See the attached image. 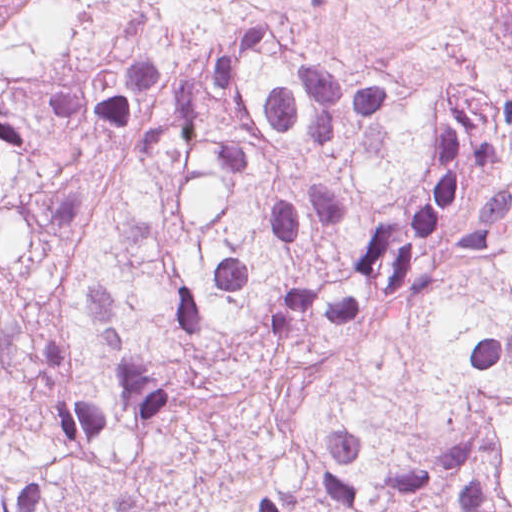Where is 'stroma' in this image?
Instances as JSON below:
<instances>
[{
	"instance_id": "obj_1",
	"label": "stroma",
	"mask_w": 512,
	"mask_h": 512,
	"mask_svg": "<svg viewBox=\"0 0 512 512\" xmlns=\"http://www.w3.org/2000/svg\"><path fill=\"white\" fill-rule=\"evenodd\" d=\"M42 8H45L44 0H11V6L8 15L14 19H19L25 15L37 13ZM155 427L156 425L153 427V429L151 430V432L149 433L148 437L146 438L142 445V449L138 459V475L134 483L133 489L131 491V496H133L134 494ZM0 512H2V501H0Z\"/></svg>"
}]
</instances>
